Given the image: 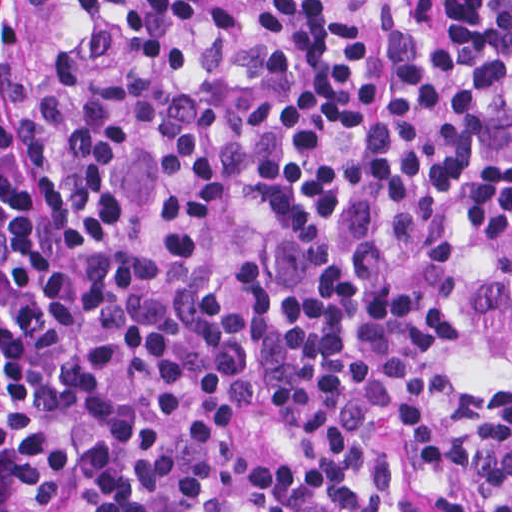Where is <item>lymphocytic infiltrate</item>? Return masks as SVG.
Wrapping results in <instances>:
<instances>
[{"label": "lymphocytic infiltrate", "mask_w": 512, "mask_h": 512, "mask_svg": "<svg viewBox=\"0 0 512 512\" xmlns=\"http://www.w3.org/2000/svg\"><path fill=\"white\" fill-rule=\"evenodd\" d=\"M1 512H512V0H1Z\"/></svg>", "instance_id": "f902f5d3"}]
</instances>
